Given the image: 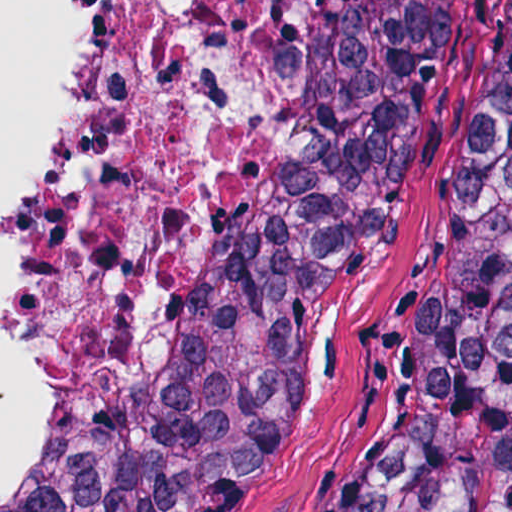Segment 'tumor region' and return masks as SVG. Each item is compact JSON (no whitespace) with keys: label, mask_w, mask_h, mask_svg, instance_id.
I'll use <instances>...</instances> for the list:
<instances>
[{"label":"tumor region","mask_w":512,"mask_h":512,"mask_svg":"<svg viewBox=\"0 0 512 512\" xmlns=\"http://www.w3.org/2000/svg\"><path fill=\"white\" fill-rule=\"evenodd\" d=\"M433 0H312L187 344L106 436L6 512H222L306 367ZM358 512H512V29L430 315L426 369Z\"/></svg>","instance_id":"obj_1"}]
</instances>
